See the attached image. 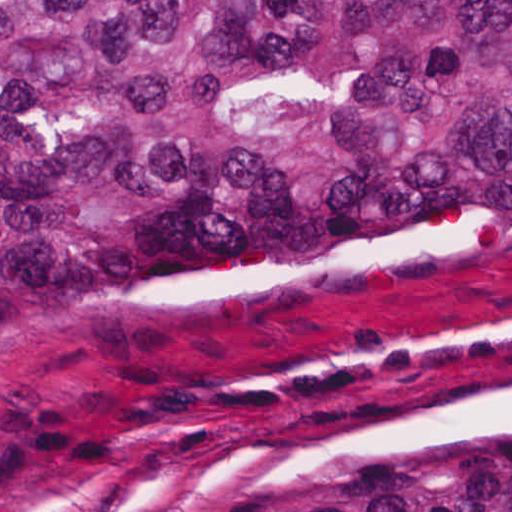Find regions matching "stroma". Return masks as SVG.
Wrapping results in <instances>:
<instances>
[{
    "label": "stroma",
    "mask_w": 512,
    "mask_h": 512,
    "mask_svg": "<svg viewBox=\"0 0 512 512\" xmlns=\"http://www.w3.org/2000/svg\"><path fill=\"white\" fill-rule=\"evenodd\" d=\"M512 420V192L223 245L127 305L1 322L0 512L308 476Z\"/></svg>",
    "instance_id": "stroma-1"
}]
</instances>
